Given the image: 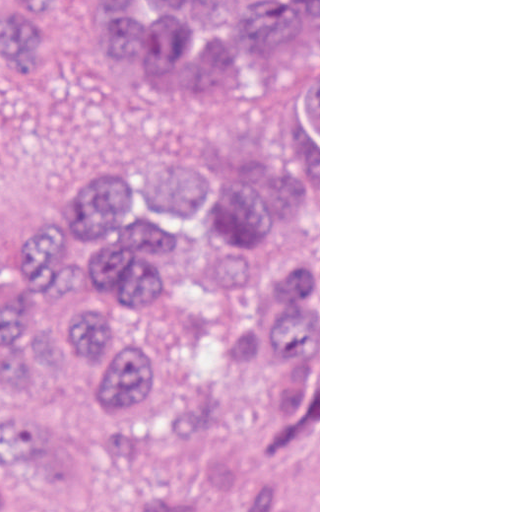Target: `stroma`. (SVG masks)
<instances>
[{"mask_svg":"<svg viewBox=\"0 0 512 512\" xmlns=\"http://www.w3.org/2000/svg\"><path fill=\"white\" fill-rule=\"evenodd\" d=\"M248 106L284 119L319 147V512H320V0L318 142L291 100L255 90ZM0 109L47 150L89 170L145 144L185 109L153 81L106 70H68L0 84Z\"/></svg>","mask_w":512,"mask_h":512,"instance_id":"1","label":"stroma"}]
</instances>
